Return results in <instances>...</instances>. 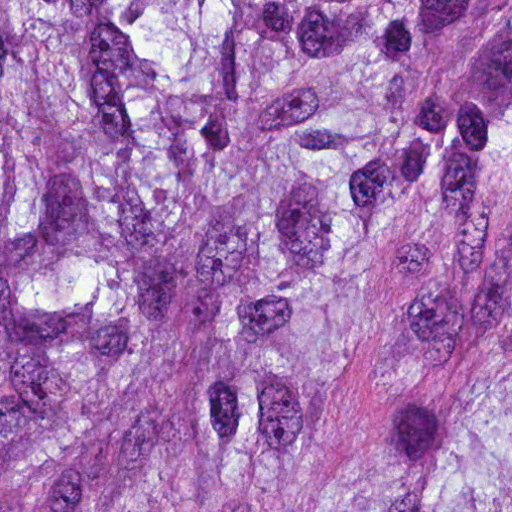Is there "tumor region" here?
<instances>
[{
	"instance_id": "obj_1",
	"label": "tumor region",
	"mask_w": 512,
	"mask_h": 512,
	"mask_svg": "<svg viewBox=\"0 0 512 512\" xmlns=\"http://www.w3.org/2000/svg\"><path fill=\"white\" fill-rule=\"evenodd\" d=\"M0 512H512V0H0Z\"/></svg>"
}]
</instances>
